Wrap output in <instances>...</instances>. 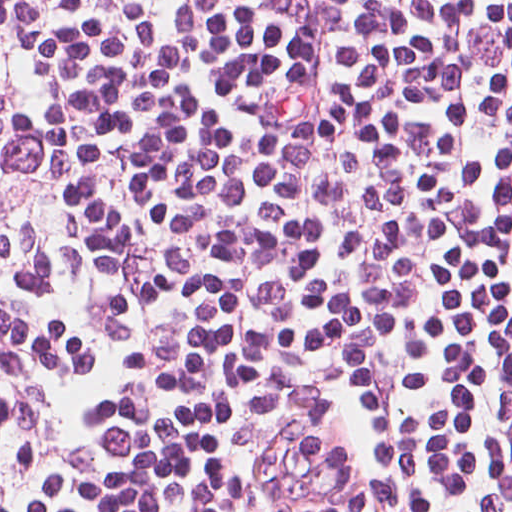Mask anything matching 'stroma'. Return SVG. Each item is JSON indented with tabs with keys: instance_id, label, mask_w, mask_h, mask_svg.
I'll return each mask as SVG.
<instances>
[{
	"instance_id": "1",
	"label": "stroma",
	"mask_w": 512,
	"mask_h": 512,
	"mask_svg": "<svg viewBox=\"0 0 512 512\" xmlns=\"http://www.w3.org/2000/svg\"><path fill=\"white\" fill-rule=\"evenodd\" d=\"M218 482L228 512H439L375 484L324 414L285 380L249 370Z\"/></svg>"
}]
</instances>
